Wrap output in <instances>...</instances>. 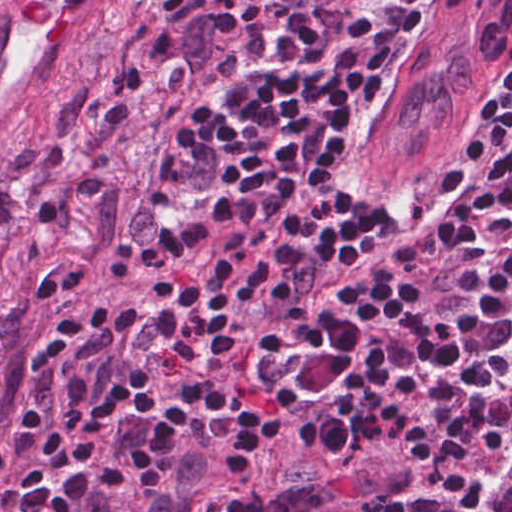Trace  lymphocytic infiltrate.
I'll list each match as a JSON object with an SVG mask.
<instances>
[{"label":"lymphocytic infiltrate","instance_id":"1","mask_svg":"<svg viewBox=\"0 0 512 512\" xmlns=\"http://www.w3.org/2000/svg\"><path fill=\"white\" fill-rule=\"evenodd\" d=\"M105 512H512V65Z\"/></svg>","mask_w":512,"mask_h":512}]
</instances>
